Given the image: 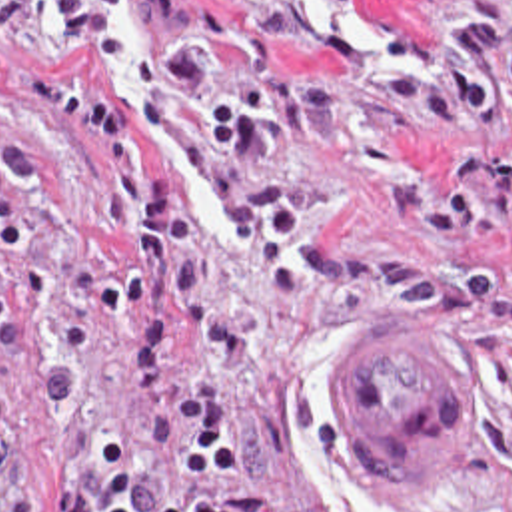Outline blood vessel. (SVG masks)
<instances>
[{
    "instance_id": "blood-vessel-1",
    "label": "blood vessel",
    "mask_w": 512,
    "mask_h": 512,
    "mask_svg": "<svg viewBox=\"0 0 512 512\" xmlns=\"http://www.w3.org/2000/svg\"><path fill=\"white\" fill-rule=\"evenodd\" d=\"M411 319L363 329L341 357L329 398L385 488L455 494L473 470L481 364L449 327Z\"/></svg>"
}]
</instances>
